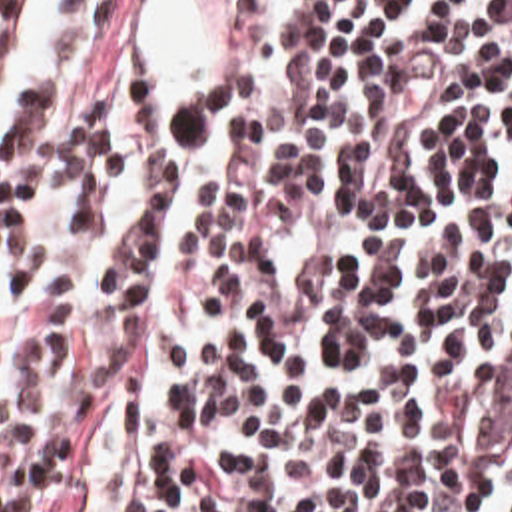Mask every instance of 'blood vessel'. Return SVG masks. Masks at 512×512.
<instances>
[{
    "label": "blood vessel",
    "mask_w": 512,
    "mask_h": 512,
    "mask_svg": "<svg viewBox=\"0 0 512 512\" xmlns=\"http://www.w3.org/2000/svg\"><path fill=\"white\" fill-rule=\"evenodd\" d=\"M484 454H512V332L498 342L496 384L484 412Z\"/></svg>",
    "instance_id": "1"
}]
</instances>
